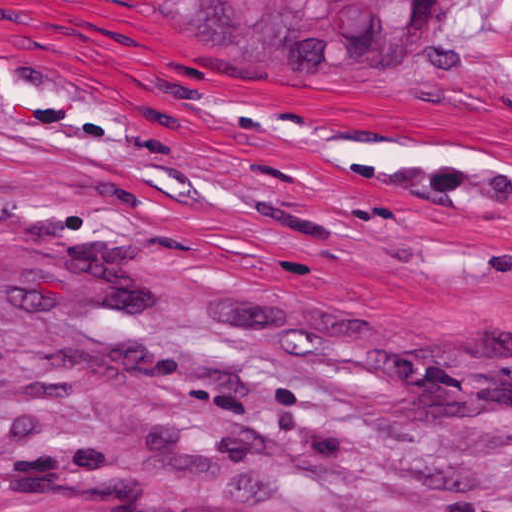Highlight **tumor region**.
I'll return each instance as SVG.
<instances>
[{
	"label": "tumor region",
	"mask_w": 512,
	"mask_h": 512,
	"mask_svg": "<svg viewBox=\"0 0 512 512\" xmlns=\"http://www.w3.org/2000/svg\"><path fill=\"white\" fill-rule=\"evenodd\" d=\"M208 51H358L437 0H87ZM0 512H274L188 478H57L0 490Z\"/></svg>",
	"instance_id": "1"
}]
</instances>
